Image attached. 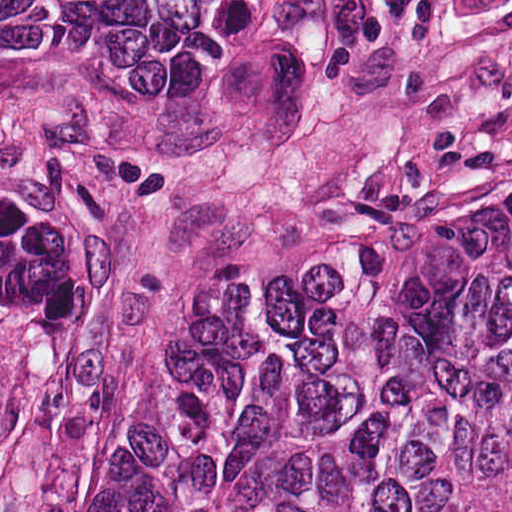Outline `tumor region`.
<instances>
[{
	"label": "tumor region",
	"instance_id": "1",
	"mask_svg": "<svg viewBox=\"0 0 512 512\" xmlns=\"http://www.w3.org/2000/svg\"><path fill=\"white\" fill-rule=\"evenodd\" d=\"M426 0H0V89L217 119L420 32ZM89 323V207L0 135V512ZM89 512H512V178L247 269Z\"/></svg>",
	"mask_w": 512,
	"mask_h": 512
}]
</instances>
